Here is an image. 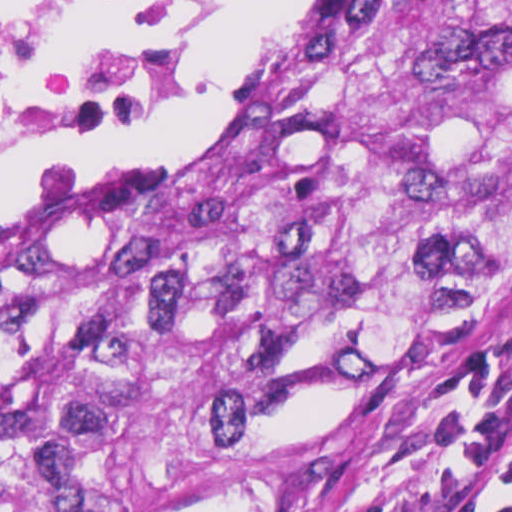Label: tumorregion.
<instances>
[{"label":"tumor region","instance_id":"1","mask_svg":"<svg viewBox=\"0 0 512 512\" xmlns=\"http://www.w3.org/2000/svg\"><path fill=\"white\" fill-rule=\"evenodd\" d=\"M512 269V0H373L218 129L0 220V512H201Z\"/></svg>","mask_w":512,"mask_h":512}]
</instances>
